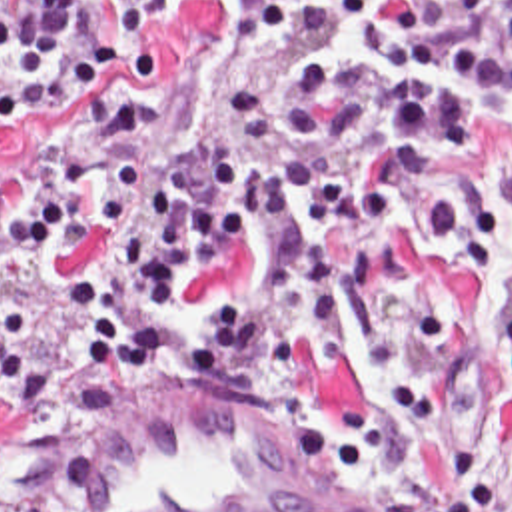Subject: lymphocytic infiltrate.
<instances>
[{
    "instance_id": "lymphocytic-infiltrate-1",
    "label": "lymphocytic infiltrate",
    "mask_w": 512,
    "mask_h": 512,
    "mask_svg": "<svg viewBox=\"0 0 512 512\" xmlns=\"http://www.w3.org/2000/svg\"><path fill=\"white\" fill-rule=\"evenodd\" d=\"M122 12V58L158 68L162 0H0V122L64 112L110 66L102 6ZM282 68H238L218 22L212 110L178 154L150 152V118L108 96L50 176L0 168V260L54 282L52 352L26 346L0 298V382L30 392L66 356L100 384L150 382L174 358L240 396L294 388V356L326 362L348 308L380 276L418 272L432 246L448 274L512 250V164L406 168L382 196L386 158L458 152L488 126L512 138V0H256ZM458 320H414L392 384L294 418L360 471L492 398L512 410V314L484 376L438 374ZM394 512H512V475L490 462L392 491Z\"/></svg>"
}]
</instances>
